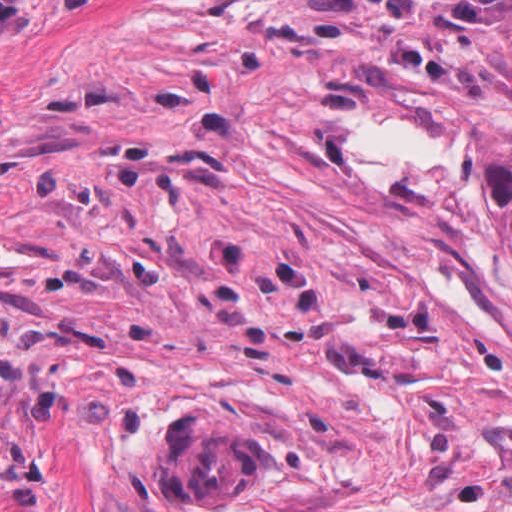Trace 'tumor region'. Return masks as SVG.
<instances>
[{
	"instance_id": "obj_1",
	"label": "tumor region",
	"mask_w": 512,
	"mask_h": 512,
	"mask_svg": "<svg viewBox=\"0 0 512 512\" xmlns=\"http://www.w3.org/2000/svg\"><path fill=\"white\" fill-rule=\"evenodd\" d=\"M161 482L199 506H236L263 476L257 427H235L195 411L171 419L156 457Z\"/></svg>"
}]
</instances>
